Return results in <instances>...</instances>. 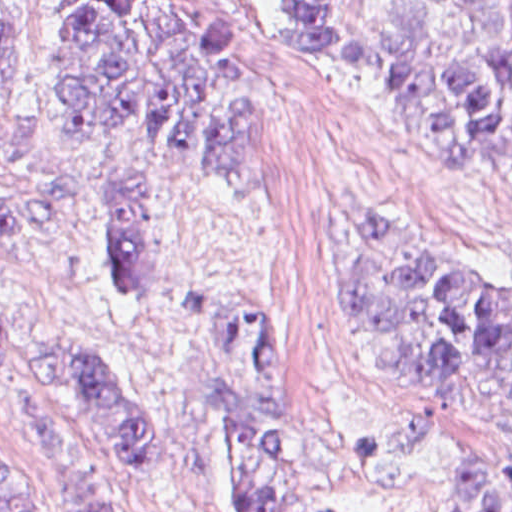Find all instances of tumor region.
<instances>
[{
	"instance_id": "obj_1",
	"label": "tumor region",
	"mask_w": 512,
	"mask_h": 512,
	"mask_svg": "<svg viewBox=\"0 0 512 512\" xmlns=\"http://www.w3.org/2000/svg\"><path fill=\"white\" fill-rule=\"evenodd\" d=\"M37 4L0 0V121L35 40ZM367 24L416 154L441 171L487 164L512 181V0H375ZM234 49L226 0H72L38 106L44 120L81 135L127 128L225 188H242L252 175V92ZM8 246L83 257L109 298L141 300L154 288L156 217L117 177L0 187V248ZM342 291L383 376L512 431L511 282L371 208L356 222ZM215 315L219 344L196 407L222 449L225 512H327L265 329L233 302ZM0 371L78 404L122 463L161 461V435L132 374L1 291ZM28 430L58 474L54 512H120L75 437ZM452 481L455 512H512V456L462 449ZM0 512H31V490L1 470Z\"/></svg>"
}]
</instances>
